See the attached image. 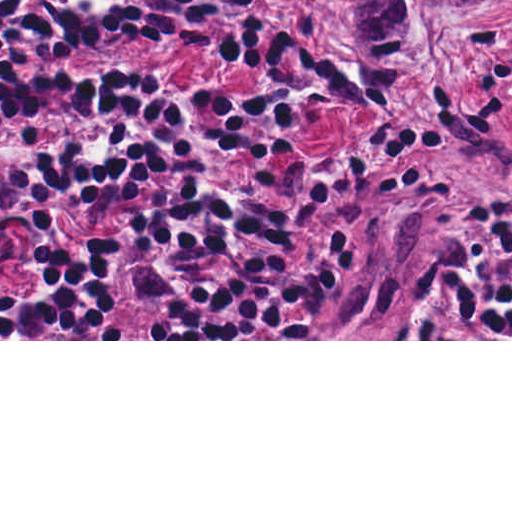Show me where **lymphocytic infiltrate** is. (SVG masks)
<instances>
[{"instance_id":"1","label":"lymphocytic infiltrate","mask_w":512,"mask_h":512,"mask_svg":"<svg viewBox=\"0 0 512 512\" xmlns=\"http://www.w3.org/2000/svg\"><path fill=\"white\" fill-rule=\"evenodd\" d=\"M24 1L0 0V18ZM306 1L326 28L317 0ZM231 3L44 0L0 33V266L11 236L50 231L66 218L106 223L34 255L24 283L0 301V339H126L109 320V290L125 270H134L140 297L158 306V339L294 337L337 297L363 237L338 236L287 270L316 206L369 179L386 183L390 196L430 141L474 114L512 70V46L486 25L436 93L366 119L333 46L310 57L269 27H243L223 60L263 83L246 94L214 93L210 120L220 143L284 148L303 109L328 101L348 114L354 144L292 166L289 192L226 191L186 146L188 94L69 68L117 38L199 50ZM447 297L475 330L512 337V221L500 228L495 276L452 273ZM386 339L446 335L427 318L396 325Z\"/></svg>"}]
</instances>
